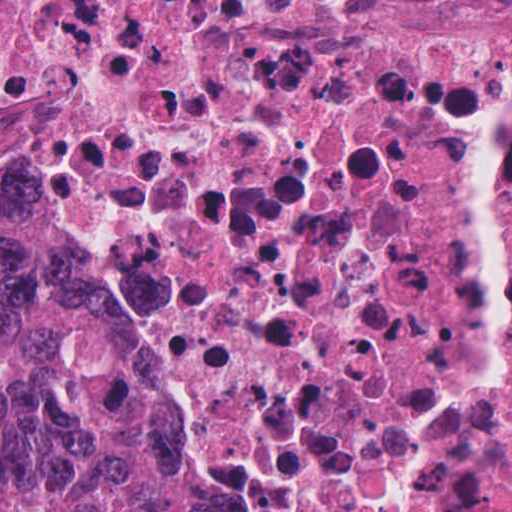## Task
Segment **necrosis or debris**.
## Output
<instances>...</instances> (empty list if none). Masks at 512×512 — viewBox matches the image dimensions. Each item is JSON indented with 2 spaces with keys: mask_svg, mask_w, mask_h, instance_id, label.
Here are the masks:
<instances>
[{
  "mask_svg": "<svg viewBox=\"0 0 512 512\" xmlns=\"http://www.w3.org/2000/svg\"><path fill=\"white\" fill-rule=\"evenodd\" d=\"M0 212L95 275L205 512H512V28L0 0Z\"/></svg>",
  "mask_w": 512,
  "mask_h": 512,
  "instance_id": "4bbe7bcc",
  "label": "necrosis or debris"
}]
</instances>
